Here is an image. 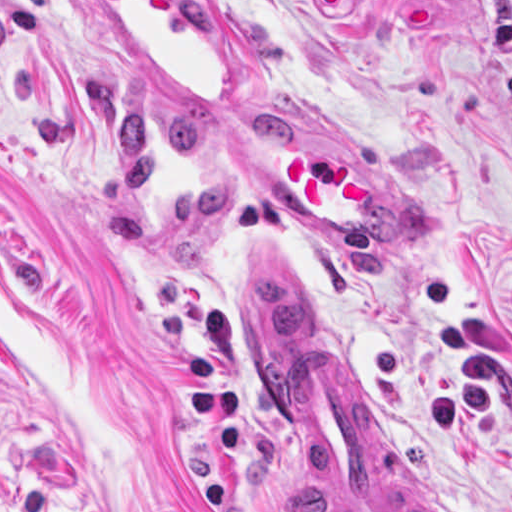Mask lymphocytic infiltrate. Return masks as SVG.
<instances>
[{"label":"lymphocytic infiltrate","mask_w":512,"mask_h":512,"mask_svg":"<svg viewBox=\"0 0 512 512\" xmlns=\"http://www.w3.org/2000/svg\"><path fill=\"white\" fill-rule=\"evenodd\" d=\"M0 512H103L96 503H85L73 509L53 508L40 489L27 490L19 495L0 489Z\"/></svg>","instance_id":"obj_1"}]
</instances>
